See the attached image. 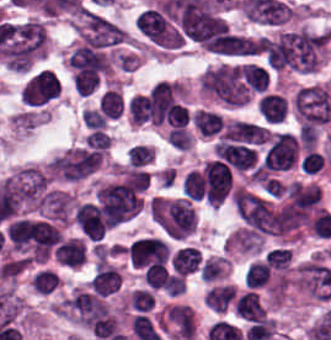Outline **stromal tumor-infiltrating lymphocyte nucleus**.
I'll return each mask as SVG.
<instances>
[{
	"label": "stromal tumor-infiltrating lymphocyte nucleus",
	"mask_w": 331,
	"mask_h": 340,
	"mask_svg": "<svg viewBox=\"0 0 331 340\" xmlns=\"http://www.w3.org/2000/svg\"><path fill=\"white\" fill-rule=\"evenodd\" d=\"M167 248L154 236L133 240L128 247L132 266H145L165 262Z\"/></svg>",
	"instance_id": "1"
},
{
	"label": "stromal tumor-infiltrating lymphocyte nucleus",
	"mask_w": 331,
	"mask_h": 340,
	"mask_svg": "<svg viewBox=\"0 0 331 340\" xmlns=\"http://www.w3.org/2000/svg\"><path fill=\"white\" fill-rule=\"evenodd\" d=\"M76 225L81 234L98 240L105 231V220L98 205L83 203L75 210Z\"/></svg>",
	"instance_id": "2"
},
{
	"label": "stromal tumor-infiltrating lymphocyte nucleus",
	"mask_w": 331,
	"mask_h": 340,
	"mask_svg": "<svg viewBox=\"0 0 331 340\" xmlns=\"http://www.w3.org/2000/svg\"><path fill=\"white\" fill-rule=\"evenodd\" d=\"M257 109L264 123L276 125L286 118L288 101L280 93L269 89L257 99Z\"/></svg>",
	"instance_id": "3"
},
{
	"label": "stromal tumor-infiltrating lymphocyte nucleus",
	"mask_w": 331,
	"mask_h": 340,
	"mask_svg": "<svg viewBox=\"0 0 331 340\" xmlns=\"http://www.w3.org/2000/svg\"><path fill=\"white\" fill-rule=\"evenodd\" d=\"M54 257L65 266H79L84 262V250L80 239H67L54 249Z\"/></svg>",
	"instance_id": "4"
},
{
	"label": "stromal tumor-infiltrating lymphocyte nucleus",
	"mask_w": 331,
	"mask_h": 340,
	"mask_svg": "<svg viewBox=\"0 0 331 340\" xmlns=\"http://www.w3.org/2000/svg\"><path fill=\"white\" fill-rule=\"evenodd\" d=\"M60 233L50 224L37 221L32 237L33 251L48 253L58 242Z\"/></svg>",
	"instance_id": "5"
},
{
	"label": "stromal tumor-infiltrating lymphocyte nucleus",
	"mask_w": 331,
	"mask_h": 340,
	"mask_svg": "<svg viewBox=\"0 0 331 340\" xmlns=\"http://www.w3.org/2000/svg\"><path fill=\"white\" fill-rule=\"evenodd\" d=\"M201 254L191 246L180 247L170 260L171 266L180 274L187 275L195 271Z\"/></svg>",
	"instance_id": "6"
},
{
	"label": "stromal tumor-infiltrating lymphocyte nucleus",
	"mask_w": 331,
	"mask_h": 340,
	"mask_svg": "<svg viewBox=\"0 0 331 340\" xmlns=\"http://www.w3.org/2000/svg\"><path fill=\"white\" fill-rule=\"evenodd\" d=\"M234 310L239 316L250 321H261L265 314L254 292H247L236 299Z\"/></svg>",
	"instance_id": "7"
},
{
	"label": "stromal tumor-infiltrating lymphocyte nucleus",
	"mask_w": 331,
	"mask_h": 340,
	"mask_svg": "<svg viewBox=\"0 0 331 340\" xmlns=\"http://www.w3.org/2000/svg\"><path fill=\"white\" fill-rule=\"evenodd\" d=\"M35 224L33 221L17 219L6 230L7 236L13 246L18 250L33 236Z\"/></svg>",
	"instance_id": "8"
},
{
	"label": "stromal tumor-infiltrating lymphocyte nucleus",
	"mask_w": 331,
	"mask_h": 340,
	"mask_svg": "<svg viewBox=\"0 0 331 340\" xmlns=\"http://www.w3.org/2000/svg\"><path fill=\"white\" fill-rule=\"evenodd\" d=\"M235 293L234 287L229 285H222L215 287L205 295L204 301L212 310H226L233 295Z\"/></svg>",
	"instance_id": "9"
},
{
	"label": "stromal tumor-infiltrating lymphocyte nucleus",
	"mask_w": 331,
	"mask_h": 340,
	"mask_svg": "<svg viewBox=\"0 0 331 340\" xmlns=\"http://www.w3.org/2000/svg\"><path fill=\"white\" fill-rule=\"evenodd\" d=\"M128 111L133 123H142L150 118V101L143 94H136L128 101Z\"/></svg>",
	"instance_id": "10"
},
{
	"label": "stromal tumor-infiltrating lymphocyte nucleus",
	"mask_w": 331,
	"mask_h": 340,
	"mask_svg": "<svg viewBox=\"0 0 331 340\" xmlns=\"http://www.w3.org/2000/svg\"><path fill=\"white\" fill-rule=\"evenodd\" d=\"M269 266L265 262H252L244 272V284L250 288L261 287L267 280Z\"/></svg>",
	"instance_id": "11"
},
{
	"label": "stromal tumor-infiltrating lymphocyte nucleus",
	"mask_w": 331,
	"mask_h": 340,
	"mask_svg": "<svg viewBox=\"0 0 331 340\" xmlns=\"http://www.w3.org/2000/svg\"><path fill=\"white\" fill-rule=\"evenodd\" d=\"M144 282L150 288H169L170 279L163 265L151 264L143 275Z\"/></svg>",
	"instance_id": "12"
},
{
	"label": "stromal tumor-infiltrating lymphocyte nucleus",
	"mask_w": 331,
	"mask_h": 340,
	"mask_svg": "<svg viewBox=\"0 0 331 340\" xmlns=\"http://www.w3.org/2000/svg\"><path fill=\"white\" fill-rule=\"evenodd\" d=\"M153 303V296L144 289H137L131 294V304L136 310H149Z\"/></svg>",
	"instance_id": "13"
},
{
	"label": "stromal tumor-infiltrating lymphocyte nucleus",
	"mask_w": 331,
	"mask_h": 340,
	"mask_svg": "<svg viewBox=\"0 0 331 340\" xmlns=\"http://www.w3.org/2000/svg\"><path fill=\"white\" fill-rule=\"evenodd\" d=\"M128 160L139 167L150 162L147 146L136 145L128 149Z\"/></svg>",
	"instance_id": "14"
}]
</instances>
